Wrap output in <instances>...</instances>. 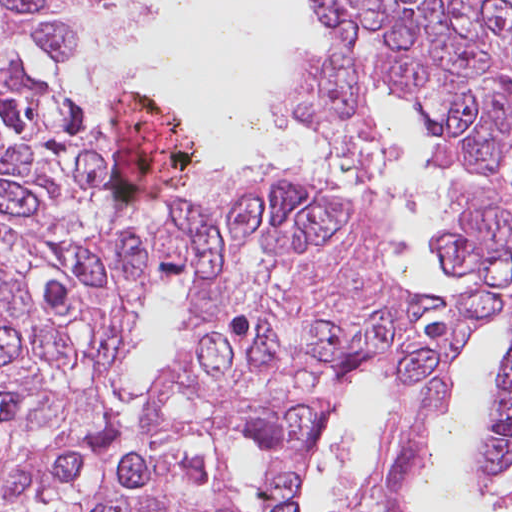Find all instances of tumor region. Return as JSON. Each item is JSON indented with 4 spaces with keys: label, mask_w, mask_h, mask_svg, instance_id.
Returning a JSON list of instances; mask_svg holds the SVG:
<instances>
[{
    "label": "tumor region",
    "mask_w": 512,
    "mask_h": 512,
    "mask_svg": "<svg viewBox=\"0 0 512 512\" xmlns=\"http://www.w3.org/2000/svg\"><path fill=\"white\" fill-rule=\"evenodd\" d=\"M318 1L335 48L294 57L272 109L365 169L386 149L368 94L407 97L447 168L448 295L402 291L375 221L282 161L116 200L67 1L0 0V512H233L245 441L261 512H300L360 379L393 432L343 512H392L448 364L502 326L471 485L512 477V0Z\"/></svg>",
    "instance_id": "e687c5a6"
}]
</instances>
